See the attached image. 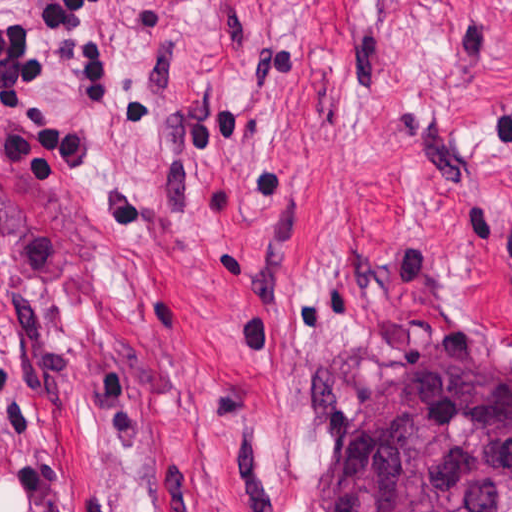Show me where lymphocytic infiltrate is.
Here are the masks:
<instances>
[{"instance_id":"lymphocytic-infiltrate-1","label":"lymphocytic infiltrate","mask_w":512,"mask_h":512,"mask_svg":"<svg viewBox=\"0 0 512 512\" xmlns=\"http://www.w3.org/2000/svg\"><path fill=\"white\" fill-rule=\"evenodd\" d=\"M47 38L74 62L72 99L85 117L111 109L108 67L88 42L96 8L108 0H28ZM50 74V50L37 46L20 0H0V128L8 170L20 184H56L78 163L86 138L69 112L40 99Z\"/></svg>"}]
</instances>
